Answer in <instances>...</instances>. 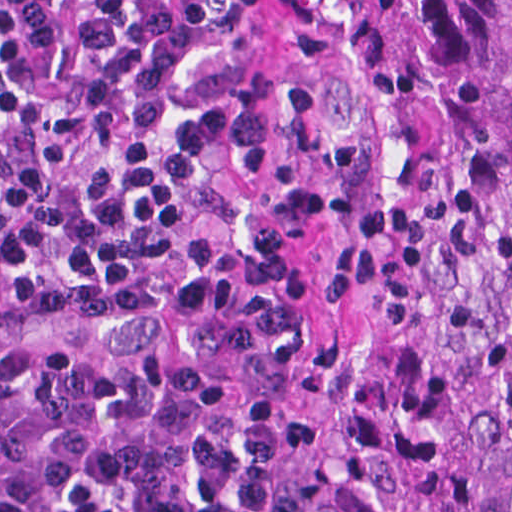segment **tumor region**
Returning a JSON list of instances; mask_svg holds the SVG:
<instances>
[{"label":"tumor region","instance_id":"1","mask_svg":"<svg viewBox=\"0 0 512 512\" xmlns=\"http://www.w3.org/2000/svg\"><path fill=\"white\" fill-rule=\"evenodd\" d=\"M324 46L328 313L178 289L95 331L286 415L307 512H512V0H332Z\"/></svg>","mask_w":512,"mask_h":512}]
</instances>
